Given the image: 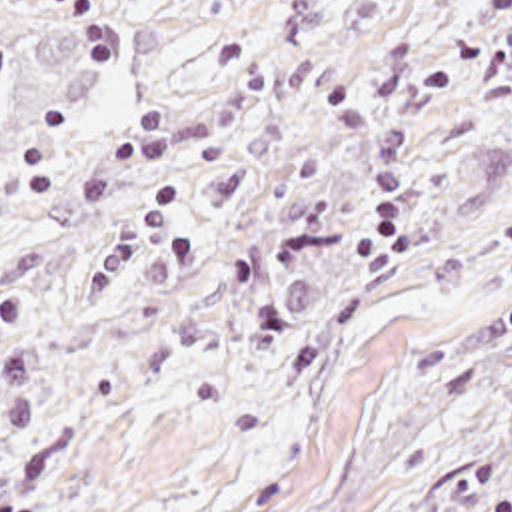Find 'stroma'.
Masks as SVG:
<instances>
[{
    "mask_svg": "<svg viewBox=\"0 0 512 512\" xmlns=\"http://www.w3.org/2000/svg\"><path fill=\"white\" fill-rule=\"evenodd\" d=\"M0 512H512V0H0Z\"/></svg>",
    "mask_w": 512,
    "mask_h": 512,
    "instance_id": "35a3bbf8",
    "label": "stroma"
}]
</instances>
